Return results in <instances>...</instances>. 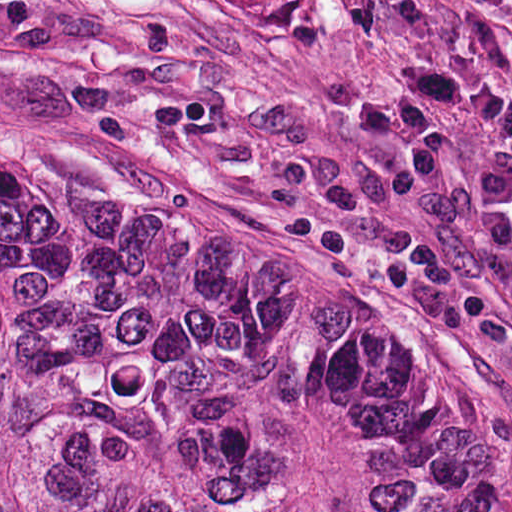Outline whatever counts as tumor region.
I'll return each instance as SVG.
<instances>
[{
	"mask_svg": "<svg viewBox=\"0 0 512 512\" xmlns=\"http://www.w3.org/2000/svg\"><path fill=\"white\" fill-rule=\"evenodd\" d=\"M0 512H512V468L370 319L0 132Z\"/></svg>",
	"mask_w": 512,
	"mask_h": 512,
	"instance_id": "1",
	"label": "tumor region"
}]
</instances>
